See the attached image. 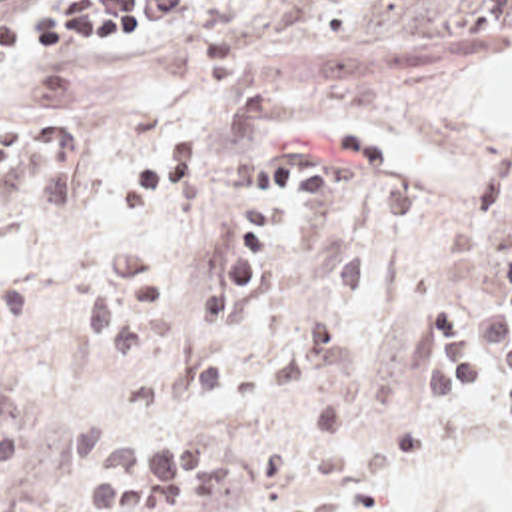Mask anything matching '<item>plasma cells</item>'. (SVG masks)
Masks as SVG:
<instances>
[{"instance_id":"obj_1","label":"plasma cells","mask_w":512,"mask_h":512,"mask_svg":"<svg viewBox=\"0 0 512 512\" xmlns=\"http://www.w3.org/2000/svg\"><path fill=\"white\" fill-rule=\"evenodd\" d=\"M474 351L492 367L512 373V251L498 269V299L472 329ZM238 488V470L200 450H119L95 460L87 480L91 512H192ZM314 512H376L370 498Z\"/></svg>"}]
</instances>
